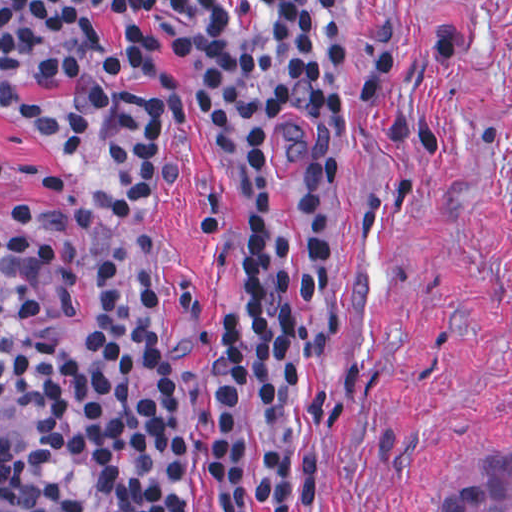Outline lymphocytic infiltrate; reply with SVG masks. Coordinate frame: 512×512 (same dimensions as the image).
<instances>
[{"instance_id": "1", "label": "lymphocytic infiltrate", "mask_w": 512, "mask_h": 512, "mask_svg": "<svg viewBox=\"0 0 512 512\" xmlns=\"http://www.w3.org/2000/svg\"><path fill=\"white\" fill-rule=\"evenodd\" d=\"M94 0H0V66L65 68L70 15ZM336 0H274L257 68L262 145L311 205L339 216L357 190L359 126L346 92ZM128 83L121 170L77 219L86 323L63 322L52 269L15 281L17 382L28 428L15 474L42 512H319L320 467L298 460L306 399V243L264 189L242 217V289L209 335L206 502L189 478V440L149 269V234L172 179L174 75L154 28L120 27Z\"/></svg>"}]
</instances>
